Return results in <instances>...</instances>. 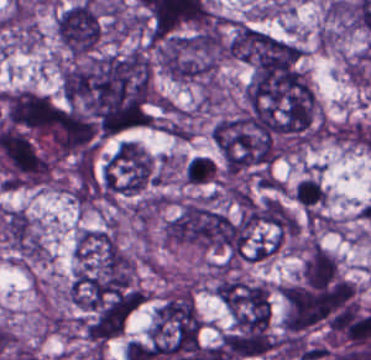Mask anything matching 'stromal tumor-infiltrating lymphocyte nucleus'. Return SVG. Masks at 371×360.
I'll return each mask as SVG.
<instances>
[{
  "label": "stromal tumor-infiltrating lymphocyte nucleus",
  "instance_id": "bc302bb0",
  "mask_svg": "<svg viewBox=\"0 0 371 360\" xmlns=\"http://www.w3.org/2000/svg\"><path fill=\"white\" fill-rule=\"evenodd\" d=\"M185 176L189 184H207L215 180L217 168L213 160L202 155H195L187 160Z\"/></svg>",
  "mask_w": 371,
  "mask_h": 360
}]
</instances>
